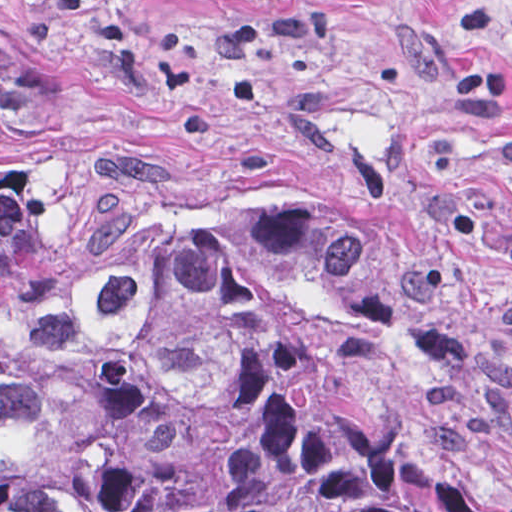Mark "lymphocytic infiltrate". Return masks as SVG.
Returning a JSON list of instances; mask_svg holds the SVG:
<instances>
[{
  "mask_svg": "<svg viewBox=\"0 0 512 512\" xmlns=\"http://www.w3.org/2000/svg\"><path fill=\"white\" fill-rule=\"evenodd\" d=\"M492 21L491 11L484 7H467L458 14L449 83L460 98L512 112V97L505 81L489 68Z\"/></svg>",
  "mask_w": 512,
  "mask_h": 512,
  "instance_id": "lymphocytic-infiltrate-1",
  "label": "lymphocytic infiltrate"
}]
</instances>
